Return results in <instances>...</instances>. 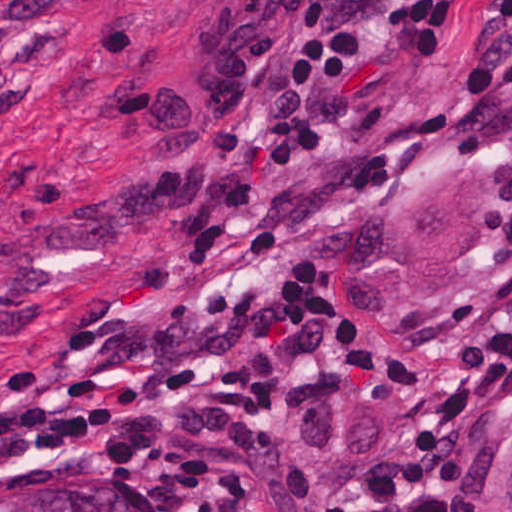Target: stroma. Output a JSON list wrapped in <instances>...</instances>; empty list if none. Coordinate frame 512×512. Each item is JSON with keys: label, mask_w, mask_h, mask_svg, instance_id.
<instances>
[{"label": "stroma", "mask_w": 512, "mask_h": 512, "mask_svg": "<svg viewBox=\"0 0 512 512\" xmlns=\"http://www.w3.org/2000/svg\"><path fill=\"white\" fill-rule=\"evenodd\" d=\"M361 81L349 0H0V512L62 474L150 512H341L405 459L423 397L362 316L420 337L512 272V64L341 222ZM446 165L504 168L492 272L447 311L369 310L361 225ZM361 512H512V386L456 486Z\"/></svg>", "instance_id": "35a3bbf8"}]
</instances>
